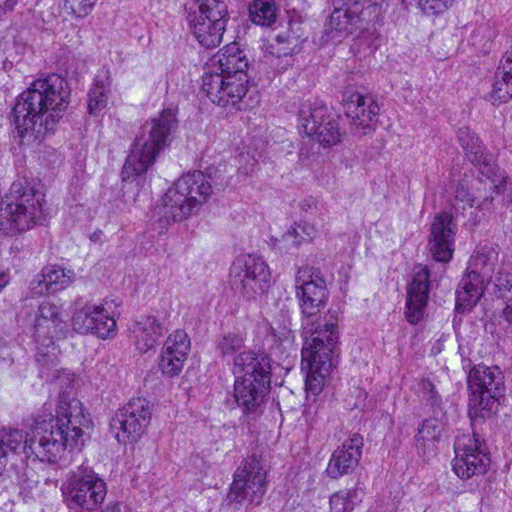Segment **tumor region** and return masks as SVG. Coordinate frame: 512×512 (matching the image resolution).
I'll return each instance as SVG.
<instances>
[{
	"label": "tumor region",
	"instance_id": "obj_1",
	"mask_svg": "<svg viewBox=\"0 0 512 512\" xmlns=\"http://www.w3.org/2000/svg\"><path fill=\"white\" fill-rule=\"evenodd\" d=\"M0 512H512V0H0Z\"/></svg>",
	"mask_w": 512,
	"mask_h": 512
}]
</instances>
